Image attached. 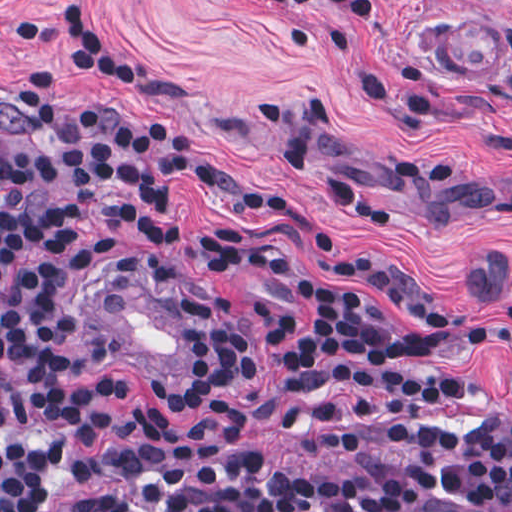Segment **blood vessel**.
<instances>
[{
    "mask_svg": "<svg viewBox=\"0 0 512 512\" xmlns=\"http://www.w3.org/2000/svg\"><path fill=\"white\" fill-rule=\"evenodd\" d=\"M88 312L91 316V295L86 301ZM194 364V338L187 327V366Z\"/></svg>",
    "mask_w": 512,
    "mask_h": 512,
    "instance_id": "8fb6f2fc",
    "label": "blood vessel"
}]
</instances>
